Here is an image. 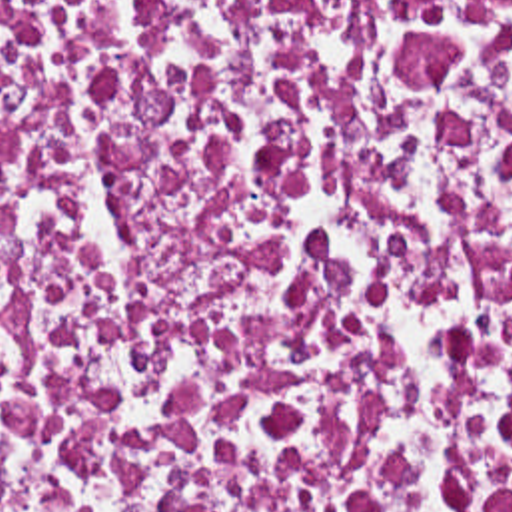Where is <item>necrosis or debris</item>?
Segmentation results:
<instances>
[{
  "label": "necrosis or debris",
  "instance_id": "4bbe7bcc",
  "mask_svg": "<svg viewBox=\"0 0 512 512\" xmlns=\"http://www.w3.org/2000/svg\"><path fill=\"white\" fill-rule=\"evenodd\" d=\"M0 512H512V0H0Z\"/></svg>",
  "mask_w": 512,
  "mask_h": 512
}]
</instances>
